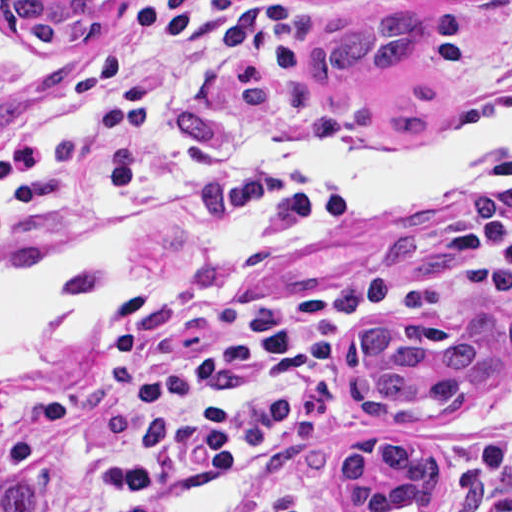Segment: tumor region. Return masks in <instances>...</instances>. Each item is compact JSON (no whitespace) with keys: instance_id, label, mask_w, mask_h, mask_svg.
<instances>
[{"instance_id":"tumor-region-1","label":"tumor region","mask_w":512,"mask_h":512,"mask_svg":"<svg viewBox=\"0 0 512 512\" xmlns=\"http://www.w3.org/2000/svg\"><path fill=\"white\" fill-rule=\"evenodd\" d=\"M105 1L0 0V19L44 47H81L96 31ZM510 2L399 0L354 12L315 42L303 92L322 106L360 99L388 138L419 142L442 117V94L425 78L436 49L431 13L449 4ZM505 330L497 314L476 317L469 335L433 321L368 328L350 350L348 398L385 419H445L512 358V326ZM333 469L342 497L366 512H434L444 496L442 471L420 443L357 441ZM493 485L489 477H469L449 512H477ZM0 512H37L36 484L9 479Z\"/></svg>"}]
</instances>
